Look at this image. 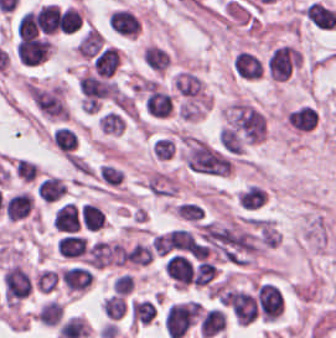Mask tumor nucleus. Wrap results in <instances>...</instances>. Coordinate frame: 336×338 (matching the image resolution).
Returning a JSON list of instances; mask_svg holds the SVG:
<instances>
[{"instance_id":"1","label":"tumor nucleus","mask_w":336,"mask_h":338,"mask_svg":"<svg viewBox=\"0 0 336 338\" xmlns=\"http://www.w3.org/2000/svg\"><path fill=\"white\" fill-rule=\"evenodd\" d=\"M260 68L261 62L251 52L243 51L240 78Z\"/></svg>"}]
</instances>
